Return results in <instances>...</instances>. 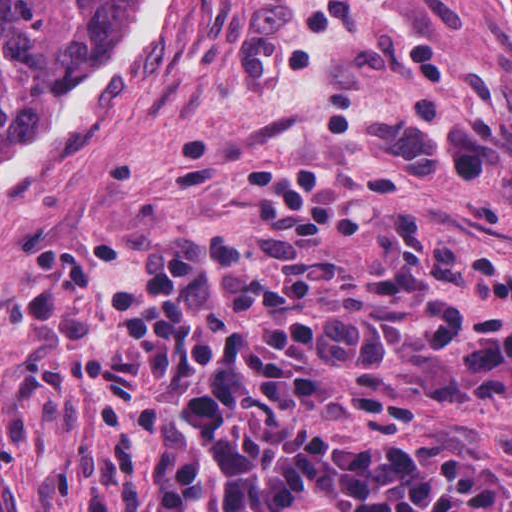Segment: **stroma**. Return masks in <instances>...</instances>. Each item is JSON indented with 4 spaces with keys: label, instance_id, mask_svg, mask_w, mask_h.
I'll use <instances>...</instances> for the list:
<instances>
[{
    "label": "stroma",
    "instance_id": "stroma-1",
    "mask_svg": "<svg viewBox=\"0 0 512 512\" xmlns=\"http://www.w3.org/2000/svg\"><path fill=\"white\" fill-rule=\"evenodd\" d=\"M123 0L110 40L124 22ZM236 161L384 170L395 205L512 269V40L486 0H176L123 91L0 180V512H84L100 466L80 338L139 243L263 229ZM455 302L512 322L482 291ZM512 491V395L423 398L411 441Z\"/></svg>",
    "mask_w": 512,
    "mask_h": 512
}]
</instances>
